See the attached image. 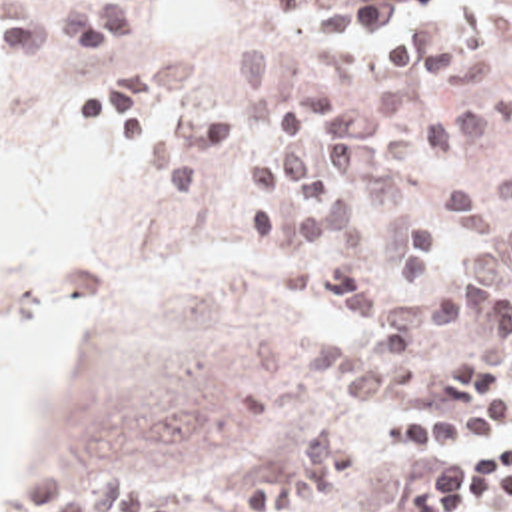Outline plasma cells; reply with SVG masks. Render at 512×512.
<instances>
[{"mask_svg":"<svg viewBox=\"0 0 512 512\" xmlns=\"http://www.w3.org/2000/svg\"><path fill=\"white\" fill-rule=\"evenodd\" d=\"M512 8V0H497ZM283 16L325 14L321 49L343 35H373L391 67L435 85H473L511 67L509 43L483 28L477 6L455 20L405 29L451 0H271ZM134 41V4L104 0L60 16H0V61L24 63L64 53L86 63ZM244 85L265 95L267 117L283 127L275 151L244 157L258 191L240 211L244 233L260 247L279 235L283 285L327 309L363 335H321L305 345L303 371L339 385L347 409L405 381L413 359L453 331L465 313L491 303L512 279V175L441 195H423L411 163L439 161L495 133L491 109L427 115L413 131L389 133L411 115V89L385 83L363 111L337 113L329 81L279 69L263 47L232 55ZM2 81V67H0ZM188 59L164 55L108 73L104 97L126 145L162 195L198 199L214 169L238 149V119L228 109L188 103ZM365 463L363 435L347 427L315 433L277 473L242 491L248 512H299L349 487ZM16 512H176L140 473L118 463L82 485L68 469L50 471Z\"/></svg>","mask_w":512,"mask_h":512,"instance_id":"9512152a","label":"plasma cells"}]
</instances>
